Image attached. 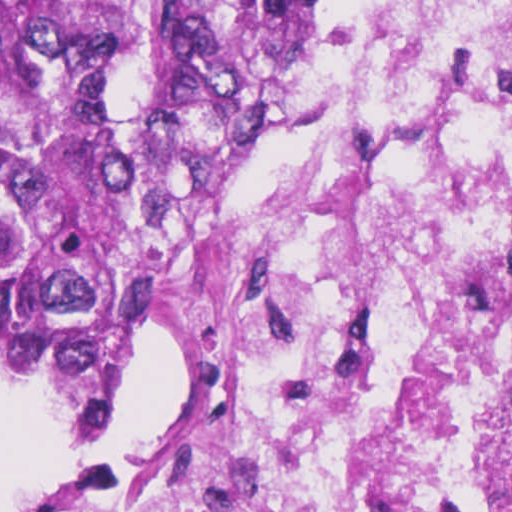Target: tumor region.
Listing matches in <instances>:
<instances>
[{"mask_svg": "<svg viewBox=\"0 0 512 512\" xmlns=\"http://www.w3.org/2000/svg\"><path fill=\"white\" fill-rule=\"evenodd\" d=\"M304 0H0V369L104 427L171 235L254 177Z\"/></svg>", "mask_w": 512, "mask_h": 512, "instance_id": "tumor-region-1", "label": "tumor region"}]
</instances>
